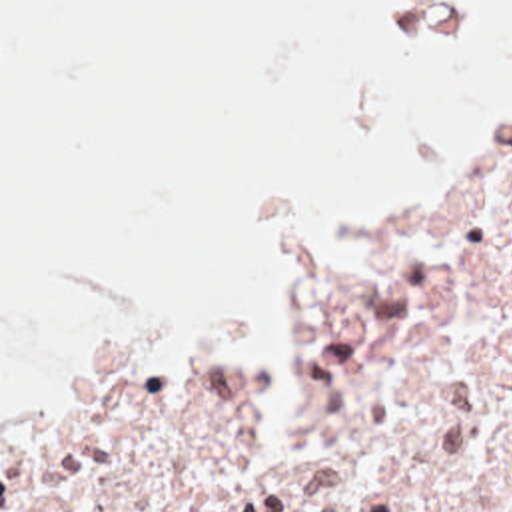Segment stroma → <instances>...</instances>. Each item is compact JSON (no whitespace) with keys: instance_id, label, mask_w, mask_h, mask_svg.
I'll return each mask as SVG.
<instances>
[{"instance_id":"35a3bbf8","label":"stroma","mask_w":512,"mask_h":512,"mask_svg":"<svg viewBox=\"0 0 512 512\" xmlns=\"http://www.w3.org/2000/svg\"><path fill=\"white\" fill-rule=\"evenodd\" d=\"M511 91L512 87L505 89L495 99L471 109L469 113H465L463 117H459L447 125L415 131V133H409L403 139H399L385 163L371 209L367 205H363L359 199L343 193L337 187H319V189L303 191V193H297V195H291V197L279 201L273 211V233L279 229V225L289 217V213L293 209H321V211L339 215L345 219V223L351 227V231L357 235V239L381 229L383 221L387 219V215L391 211V203H393L395 157L419 153L423 149H429L433 145H439L447 139H453V137L465 133ZM275 303H277L279 315H281V347H279L277 355L265 345L263 337L253 331L235 329V327H188L184 331H178V333L154 343V345H148V347L132 353L124 361H120L92 377L68 381L60 387L46 389V391H40L32 397L24 399L14 411H10L6 417L0 419V440L34 421L42 419L44 415L52 413L54 409L62 407L64 403H68L84 393H90L94 389H100L104 385H110L114 381L144 377V375L156 373L160 369L178 365V363L216 357V355H251V357L267 359L269 377H271V430L293 440L297 434V428L301 425V399H299V393H297L291 369H289V361L285 355V327H287L289 311L277 299V295H275Z\"/></svg>"}]
</instances>
